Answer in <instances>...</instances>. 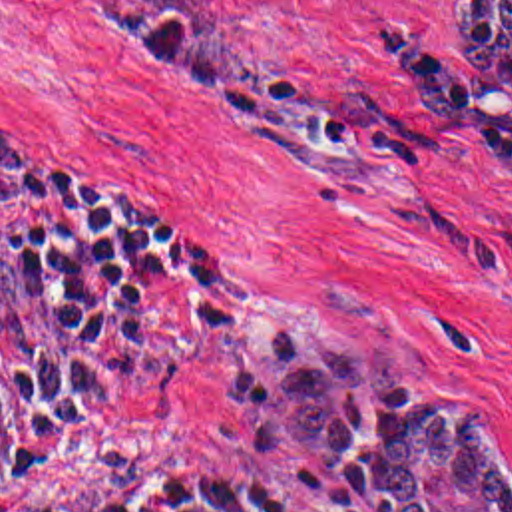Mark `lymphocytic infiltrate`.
<instances>
[{
  "label": "lymphocytic infiltrate",
  "instance_id": "lymphocytic-infiltrate-1",
  "mask_svg": "<svg viewBox=\"0 0 512 512\" xmlns=\"http://www.w3.org/2000/svg\"><path fill=\"white\" fill-rule=\"evenodd\" d=\"M173 280L221 316V270L179 221L0 127V512H48L36 469ZM127 512L340 511L257 469H203L153 481Z\"/></svg>",
  "mask_w": 512,
  "mask_h": 512
}]
</instances>
